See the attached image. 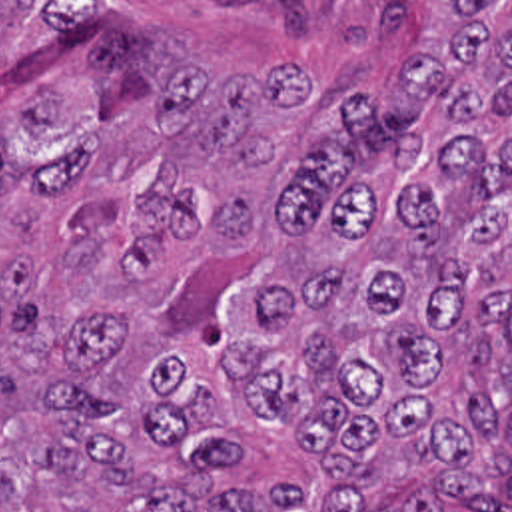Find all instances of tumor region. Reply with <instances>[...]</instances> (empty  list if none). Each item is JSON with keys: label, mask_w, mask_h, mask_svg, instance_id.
I'll use <instances>...</instances> for the list:
<instances>
[{"label": "tumor region", "mask_w": 512, "mask_h": 512, "mask_svg": "<svg viewBox=\"0 0 512 512\" xmlns=\"http://www.w3.org/2000/svg\"><path fill=\"white\" fill-rule=\"evenodd\" d=\"M374 91L0 0V512L512 498V0Z\"/></svg>", "instance_id": "tumor-region-1"}]
</instances>
